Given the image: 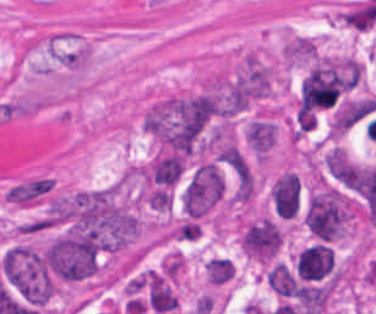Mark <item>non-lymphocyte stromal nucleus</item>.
Returning a JSON list of instances; mask_svg holds the SVG:
<instances>
[{"label": "non-lymphocyte stromal nucleus", "instance_id": "1", "mask_svg": "<svg viewBox=\"0 0 376 314\" xmlns=\"http://www.w3.org/2000/svg\"><path fill=\"white\" fill-rule=\"evenodd\" d=\"M52 189V183L46 178H33L13 186L5 193L6 199L19 205H32L46 192Z\"/></svg>", "mask_w": 376, "mask_h": 314}]
</instances>
